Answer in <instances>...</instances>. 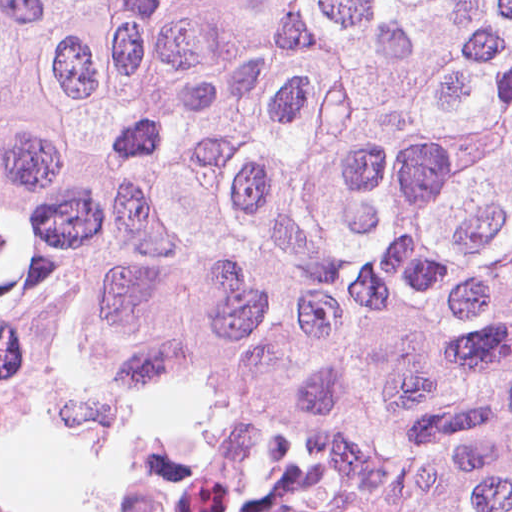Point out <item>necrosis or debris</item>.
Masks as SVG:
<instances>
[{
    "instance_id": "necrosis-or-debris-1",
    "label": "necrosis or debris",
    "mask_w": 512,
    "mask_h": 512,
    "mask_svg": "<svg viewBox=\"0 0 512 512\" xmlns=\"http://www.w3.org/2000/svg\"><path fill=\"white\" fill-rule=\"evenodd\" d=\"M27 413L49 415L67 426L100 436L112 428L96 414L54 406L0 379V431L12 428L16 419ZM0 512L9 511L0 507ZM116 512H165L144 465Z\"/></svg>"
}]
</instances>
